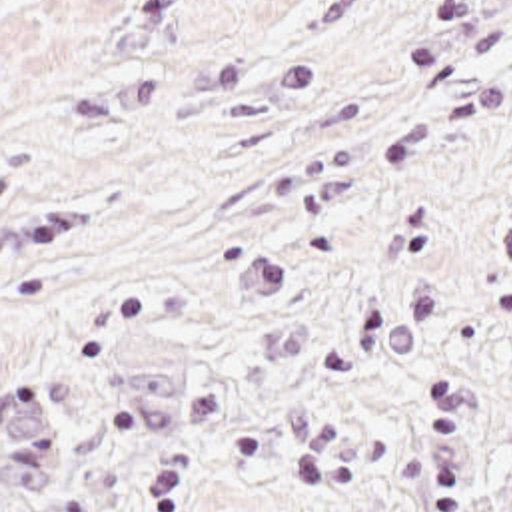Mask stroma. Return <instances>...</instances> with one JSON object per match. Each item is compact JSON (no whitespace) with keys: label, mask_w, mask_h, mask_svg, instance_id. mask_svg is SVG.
<instances>
[{"label":"stroma","mask_w":512,"mask_h":512,"mask_svg":"<svg viewBox=\"0 0 512 512\" xmlns=\"http://www.w3.org/2000/svg\"><path fill=\"white\" fill-rule=\"evenodd\" d=\"M0 512H512V0H0Z\"/></svg>","instance_id":"1"}]
</instances>
